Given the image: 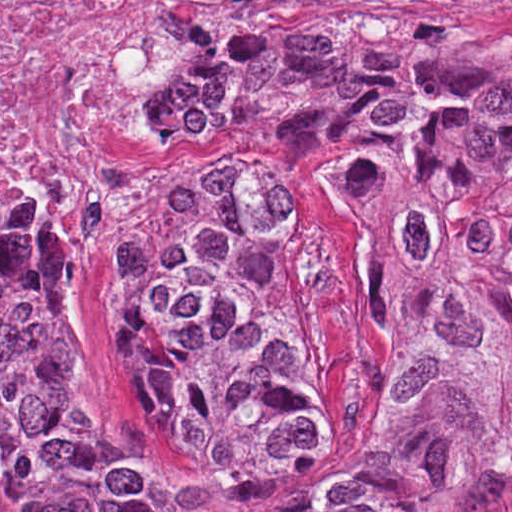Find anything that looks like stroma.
<instances>
[{
	"label": "stroma",
	"mask_w": 512,
	"mask_h": 512,
	"mask_svg": "<svg viewBox=\"0 0 512 512\" xmlns=\"http://www.w3.org/2000/svg\"><path fill=\"white\" fill-rule=\"evenodd\" d=\"M440 13L512 32V0H346ZM193 53V52H192ZM189 59L161 104L159 133L175 119ZM161 139V138H160ZM175 145L161 140L159 176ZM269 177L309 253L318 285V344L334 397L318 418L263 435L241 457L187 483L212 450L163 422L154 386L125 332V288L89 295L58 252L91 342L86 432L120 468L176 479L268 512H317L362 471L393 430L399 287L348 214L356 161H303L222 147ZM159 178V177H158ZM0 512H1V0H0ZM464 512H512V476L496 479Z\"/></svg>",
	"instance_id": "obj_1"
}]
</instances>
